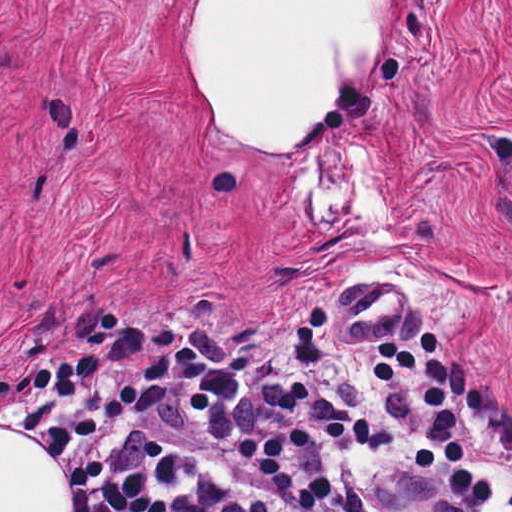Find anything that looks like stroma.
<instances>
[{
  "mask_svg": "<svg viewBox=\"0 0 512 512\" xmlns=\"http://www.w3.org/2000/svg\"><path fill=\"white\" fill-rule=\"evenodd\" d=\"M185 1L0 0V375L103 356L78 400L98 412L188 345L207 375L116 427L259 498L229 448L292 424L289 385L371 421L375 347L431 331L492 496L418 467L421 373L394 391L391 441L315 443L292 479L332 480L308 512H510L512 0H399L385 54L282 159L205 117L174 51ZM1 431L20 433L0 428V512Z\"/></svg>",
  "mask_w": 512,
  "mask_h": 512,
  "instance_id": "stroma-1",
  "label": "stroma"
}]
</instances>
